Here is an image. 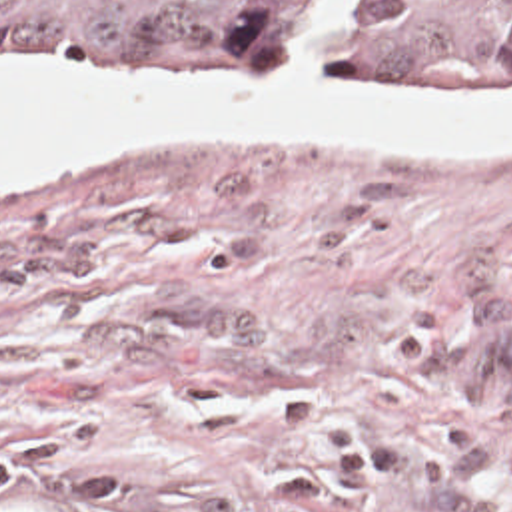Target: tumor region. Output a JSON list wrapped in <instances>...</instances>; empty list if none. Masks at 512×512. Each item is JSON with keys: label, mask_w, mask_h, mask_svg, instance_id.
<instances>
[{"label": "tumor region", "mask_w": 512, "mask_h": 512, "mask_svg": "<svg viewBox=\"0 0 512 512\" xmlns=\"http://www.w3.org/2000/svg\"><path fill=\"white\" fill-rule=\"evenodd\" d=\"M0 61H136L208 77H419L512 95V0H0ZM0 512L30 510L0 490Z\"/></svg>", "instance_id": "tumor-region-1"}]
</instances>
